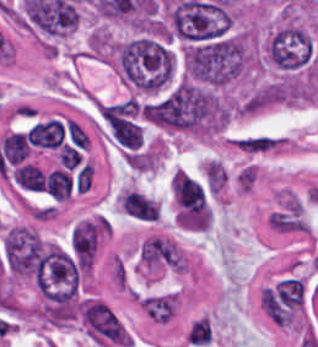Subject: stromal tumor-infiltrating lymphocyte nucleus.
<instances>
[{
  "label": "stromal tumor-infiltrating lymphocyte nucleus",
  "instance_id": "obj_1",
  "mask_svg": "<svg viewBox=\"0 0 318 347\" xmlns=\"http://www.w3.org/2000/svg\"><path fill=\"white\" fill-rule=\"evenodd\" d=\"M175 310V295L173 293V296H172V300H171V304H170V308H169V312H168V316H167V320H166V323L169 322L173 312Z\"/></svg>",
  "mask_w": 318,
  "mask_h": 347
}]
</instances>
